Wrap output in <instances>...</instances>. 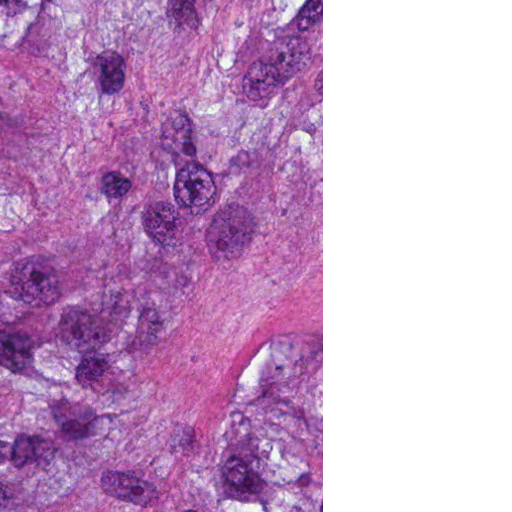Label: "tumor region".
I'll use <instances>...</instances> for the list:
<instances>
[{"label":"tumor region","mask_w":512,"mask_h":512,"mask_svg":"<svg viewBox=\"0 0 512 512\" xmlns=\"http://www.w3.org/2000/svg\"><path fill=\"white\" fill-rule=\"evenodd\" d=\"M0 512H161V0H0Z\"/></svg>","instance_id":"1"}]
</instances>
